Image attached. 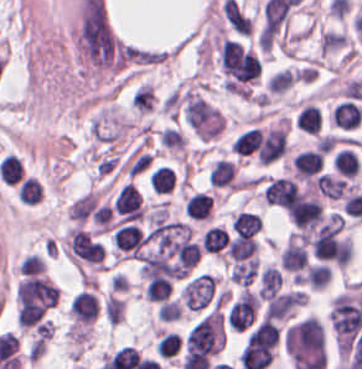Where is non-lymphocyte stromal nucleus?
Returning a JSON list of instances; mask_svg holds the SVG:
<instances>
[{"mask_svg": "<svg viewBox=\"0 0 362 369\" xmlns=\"http://www.w3.org/2000/svg\"><path fill=\"white\" fill-rule=\"evenodd\" d=\"M216 288L213 275L200 273L187 281L180 291L181 304L190 312H198L211 299Z\"/></svg>", "mask_w": 362, "mask_h": 369, "instance_id": "1", "label": "non-lymphocyte stromal nucleus"}]
</instances>
